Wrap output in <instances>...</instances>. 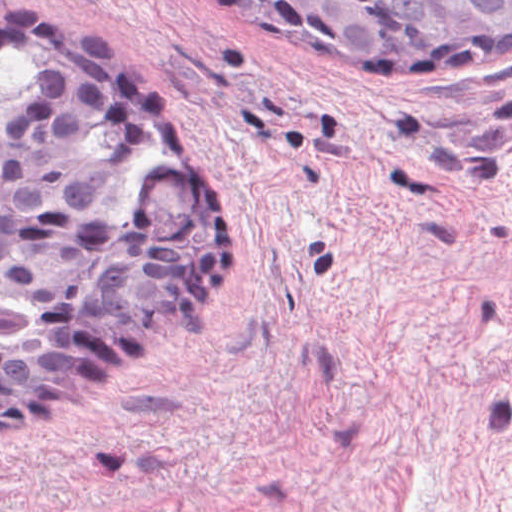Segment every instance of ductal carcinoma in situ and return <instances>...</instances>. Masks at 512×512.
<instances>
[{
    "label": "ductal carcinoma in situ",
    "mask_w": 512,
    "mask_h": 512,
    "mask_svg": "<svg viewBox=\"0 0 512 512\" xmlns=\"http://www.w3.org/2000/svg\"><path fill=\"white\" fill-rule=\"evenodd\" d=\"M323 50L512 67V0H241ZM37 83L0 94V430H21L214 290L231 208L145 102L49 33L0 28Z\"/></svg>",
    "instance_id": "ductal-carcinoma-in-situ-1"
}]
</instances>
